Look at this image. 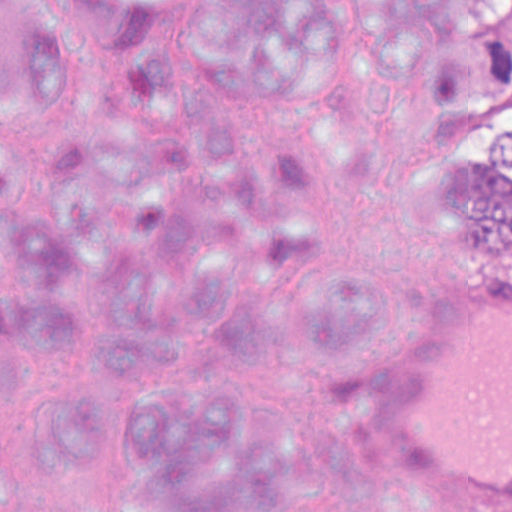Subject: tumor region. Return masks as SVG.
<instances>
[{
    "label": "tumor region",
    "mask_w": 512,
    "mask_h": 512,
    "mask_svg": "<svg viewBox=\"0 0 512 512\" xmlns=\"http://www.w3.org/2000/svg\"><path fill=\"white\" fill-rule=\"evenodd\" d=\"M400 73H422L461 221L489 257L512 256V0H371Z\"/></svg>",
    "instance_id": "e687c5a6"
}]
</instances>
